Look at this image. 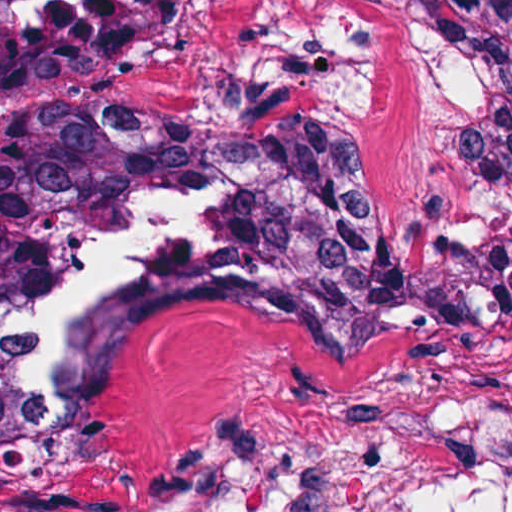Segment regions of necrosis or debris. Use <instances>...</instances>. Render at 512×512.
Instances as JSON below:
<instances>
[{
  "mask_svg": "<svg viewBox=\"0 0 512 512\" xmlns=\"http://www.w3.org/2000/svg\"><path fill=\"white\" fill-rule=\"evenodd\" d=\"M151 1L0 0V259L31 282L2 319L0 370L37 423L99 409L124 312L162 281L314 249L366 203L334 151L122 117Z\"/></svg>",
  "mask_w": 512,
  "mask_h": 512,
  "instance_id": "4bbe7bcc",
  "label": "necrosis or debris"
}]
</instances>
